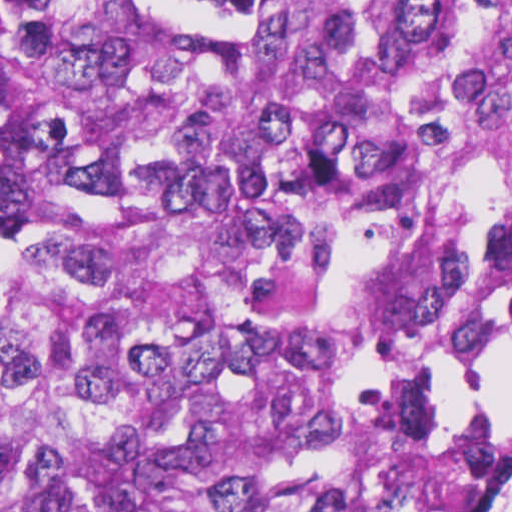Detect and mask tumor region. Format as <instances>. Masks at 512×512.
<instances>
[{
	"label": "tumor region",
	"mask_w": 512,
	"mask_h": 512,
	"mask_svg": "<svg viewBox=\"0 0 512 512\" xmlns=\"http://www.w3.org/2000/svg\"><path fill=\"white\" fill-rule=\"evenodd\" d=\"M0 512H481L512 0H0Z\"/></svg>",
	"instance_id": "1"
}]
</instances>
